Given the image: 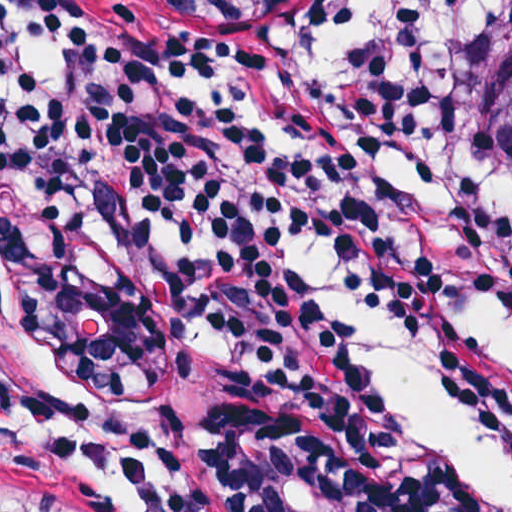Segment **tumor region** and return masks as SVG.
Listing matches in <instances>:
<instances>
[{
    "label": "tumor region",
    "mask_w": 512,
    "mask_h": 512,
    "mask_svg": "<svg viewBox=\"0 0 512 512\" xmlns=\"http://www.w3.org/2000/svg\"><path fill=\"white\" fill-rule=\"evenodd\" d=\"M461 154L464 168L512 208V0H496L479 39Z\"/></svg>",
    "instance_id": "1"
}]
</instances>
